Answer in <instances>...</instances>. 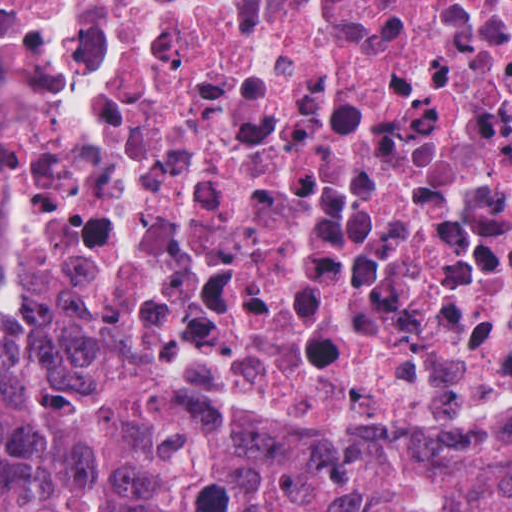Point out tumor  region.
Returning a JSON list of instances; mask_svg holds the SVG:
<instances>
[{
    "mask_svg": "<svg viewBox=\"0 0 512 512\" xmlns=\"http://www.w3.org/2000/svg\"><path fill=\"white\" fill-rule=\"evenodd\" d=\"M0 512H512V433L234 420L111 358L75 276L0 204Z\"/></svg>",
    "mask_w": 512,
    "mask_h": 512,
    "instance_id": "obj_1",
    "label": "tumor region"
}]
</instances>
